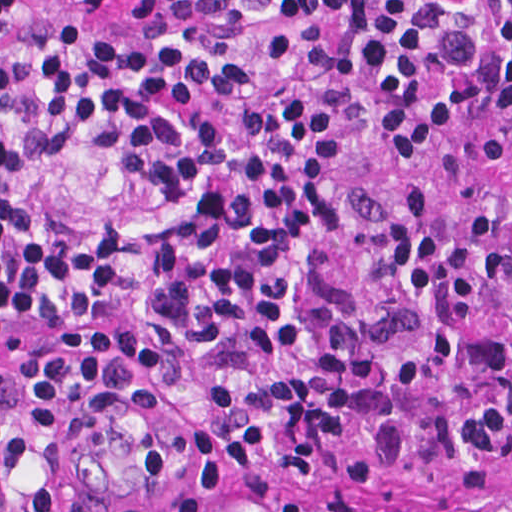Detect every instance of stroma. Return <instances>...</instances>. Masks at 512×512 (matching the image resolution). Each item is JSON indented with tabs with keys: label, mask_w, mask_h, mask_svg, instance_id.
I'll use <instances>...</instances> for the list:
<instances>
[{
	"label": "stroma",
	"mask_w": 512,
	"mask_h": 512,
	"mask_svg": "<svg viewBox=\"0 0 512 512\" xmlns=\"http://www.w3.org/2000/svg\"><path fill=\"white\" fill-rule=\"evenodd\" d=\"M98 21L134 41L190 42L238 53L258 70L251 98L192 103L198 131H231L283 100H323L338 117V154L325 185L335 222L300 244L316 348L269 353L251 331H235L219 352L192 348L153 316L150 248L184 219L132 164L91 148L51 158L39 130L46 111L44 46L69 26ZM375 84L342 24H286L269 0H26L0 41V125L18 147L35 209L60 240L112 225L124 230L121 299L108 320H24L0 308V395L64 353L123 358L133 381L86 441L84 484L109 496L149 498L210 488L189 474L194 430L210 395L311 362L322 354L339 298L370 279L386 247L384 223L404 187L434 203L439 223L490 199L509 197L512 105L476 109L447 148L383 157L371 118ZM219 512H335L346 501H418L451 512H512V450L454 470L418 472L367 490L334 478H295L256 494L232 490Z\"/></svg>",
	"instance_id": "obj_1"
}]
</instances>
